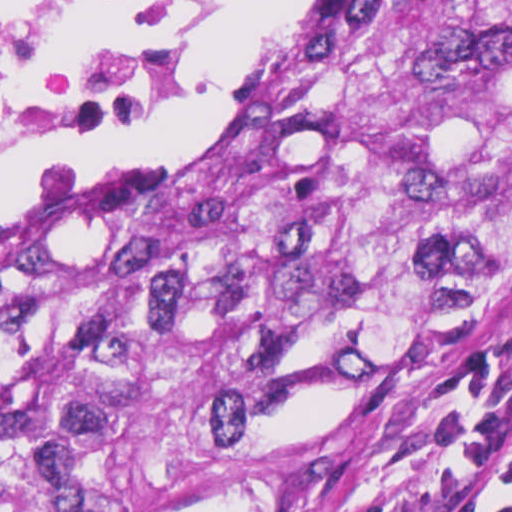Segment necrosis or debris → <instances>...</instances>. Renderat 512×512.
<instances>
[{
	"instance_id": "necrosis-or-debris-1",
	"label": "necrosis or debris",
	"mask_w": 512,
	"mask_h": 512,
	"mask_svg": "<svg viewBox=\"0 0 512 512\" xmlns=\"http://www.w3.org/2000/svg\"><path fill=\"white\" fill-rule=\"evenodd\" d=\"M206 30L205 0H0V166L151 127Z\"/></svg>"
}]
</instances>
